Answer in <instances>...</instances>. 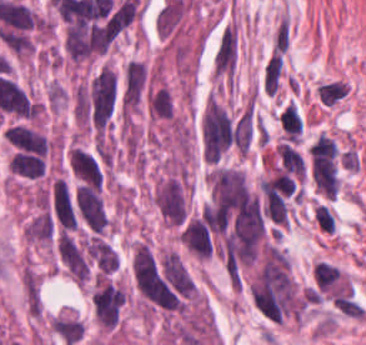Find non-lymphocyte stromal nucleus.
<instances>
[{
  "mask_svg": "<svg viewBox=\"0 0 366 345\" xmlns=\"http://www.w3.org/2000/svg\"><path fill=\"white\" fill-rule=\"evenodd\" d=\"M347 93V83L338 79L318 85V95L322 104H336Z\"/></svg>",
  "mask_w": 366,
  "mask_h": 345,
  "instance_id": "non-lymphocyte-stromal-nucleus-3",
  "label": "non-lymphocyte stromal nucleus"
},
{
  "mask_svg": "<svg viewBox=\"0 0 366 345\" xmlns=\"http://www.w3.org/2000/svg\"><path fill=\"white\" fill-rule=\"evenodd\" d=\"M283 66L281 54L274 53L267 61L264 75L263 90L273 94L278 87L280 74Z\"/></svg>",
  "mask_w": 366,
  "mask_h": 345,
  "instance_id": "non-lymphocyte-stromal-nucleus-2",
  "label": "non-lymphocyte stromal nucleus"
},
{
  "mask_svg": "<svg viewBox=\"0 0 366 345\" xmlns=\"http://www.w3.org/2000/svg\"><path fill=\"white\" fill-rule=\"evenodd\" d=\"M238 50V27L228 20L218 33L212 56V76L215 80L232 86L237 75Z\"/></svg>",
  "mask_w": 366,
  "mask_h": 345,
  "instance_id": "non-lymphocyte-stromal-nucleus-1",
  "label": "non-lymphocyte stromal nucleus"
},
{
  "mask_svg": "<svg viewBox=\"0 0 366 345\" xmlns=\"http://www.w3.org/2000/svg\"><path fill=\"white\" fill-rule=\"evenodd\" d=\"M315 210H316L317 223L320 226V228L327 232L333 233L334 223L331 208L318 203L315 206Z\"/></svg>",
  "mask_w": 366,
  "mask_h": 345,
  "instance_id": "non-lymphocyte-stromal-nucleus-4",
  "label": "non-lymphocyte stromal nucleus"
}]
</instances>
